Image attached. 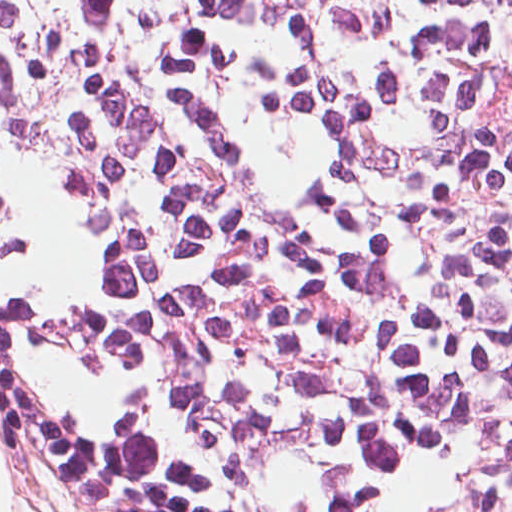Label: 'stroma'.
I'll return each instance as SVG.
<instances>
[{
	"mask_svg": "<svg viewBox=\"0 0 512 512\" xmlns=\"http://www.w3.org/2000/svg\"><path fill=\"white\" fill-rule=\"evenodd\" d=\"M0 448L12 468L9 512H73L67 500L24 459L1 427Z\"/></svg>",
	"mask_w": 512,
	"mask_h": 512,
	"instance_id": "obj_1",
	"label": "stroma"
}]
</instances>
